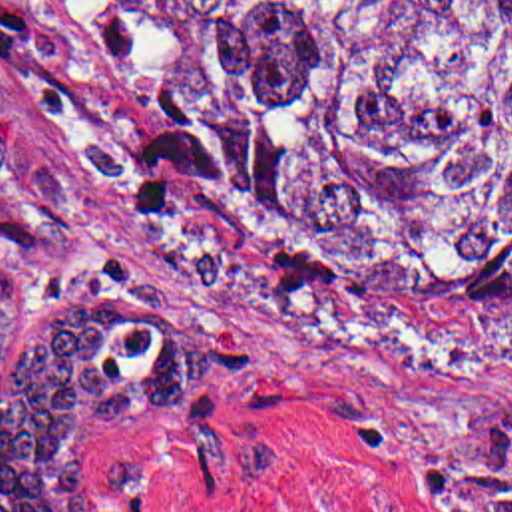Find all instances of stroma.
<instances>
[{"label": "stroma", "mask_w": 512, "mask_h": 512, "mask_svg": "<svg viewBox=\"0 0 512 512\" xmlns=\"http://www.w3.org/2000/svg\"><path fill=\"white\" fill-rule=\"evenodd\" d=\"M181 121L179 65L135 0H0V382L109 257L169 292L217 372L79 438L99 512H448L472 428L512 418L483 286L306 255L181 155Z\"/></svg>", "instance_id": "1"}]
</instances>
